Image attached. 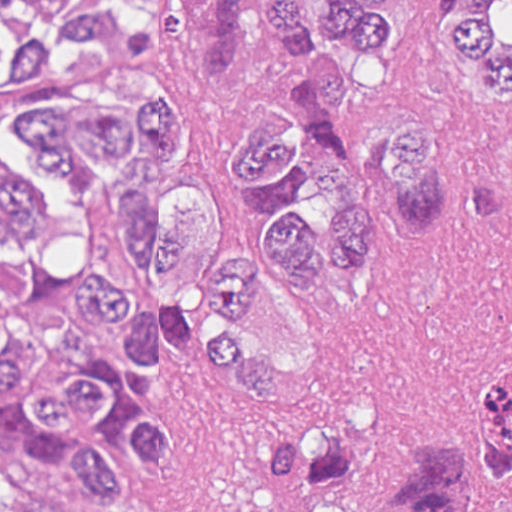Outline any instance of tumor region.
Here are the masks:
<instances>
[{
    "instance_id": "e687c5a6",
    "label": "tumor region",
    "mask_w": 512,
    "mask_h": 512,
    "mask_svg": "<svg viewBox=\"0 0 512 512\" xmlns=\"http://www.w3.org/2000/svg\"><path fill=\"white\" fill-rule=\"evenodd\" d=\"M179 45L206 78L226 76L255 0H175ZM264 30L290 44L273 101H254L223 148L257 237L224 250L214 195L175 168L186 135L152 81L160 0H0V108L43 169L71 181L75 215L0 161V458L30 470L75 463L92 502L131 498L117 445L175 463L169 427L141 415L131 381L159 336L193 343L240 398L277 399L286 370L232 315L257 301L264 264L298 302L364 265L382 228L423 238L446 221V122L412 126L396 160L361 170L339 130L390 34L392 0H261ZM441 22L488 109L512 114V0H441ZM312 137L315 148L307 144ZM315 189L333 211L308 229ZM512 506V371L479 416L413 448L339 427L283 432L236 469L220 512H489Z\"/></svg>"
}]
</instances>
